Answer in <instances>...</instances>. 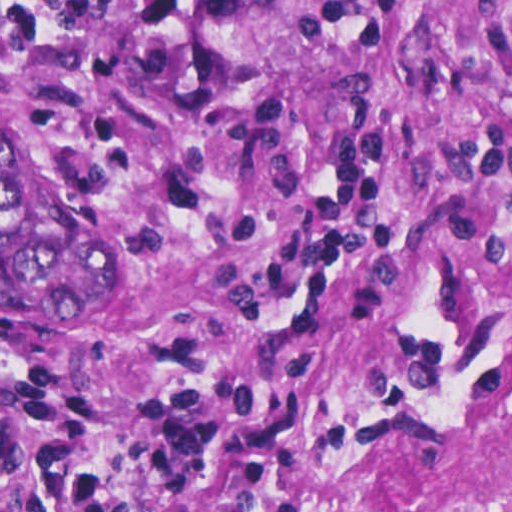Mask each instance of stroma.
Here are the masks:
<instances>
[{"instance_id": "1", "label": "stroma", "mask_w": 512, "mask_h": 512, "mask_svg": "<svg viewBox=\"0 0 512 512\" xmlns=\"http://www.w3.org/2000/svg\"><path fill=\"white\" fill-rule=\"evenodd\" d=\"M0 512H512V0H0Z\"/></svg>"}]
</instances>
